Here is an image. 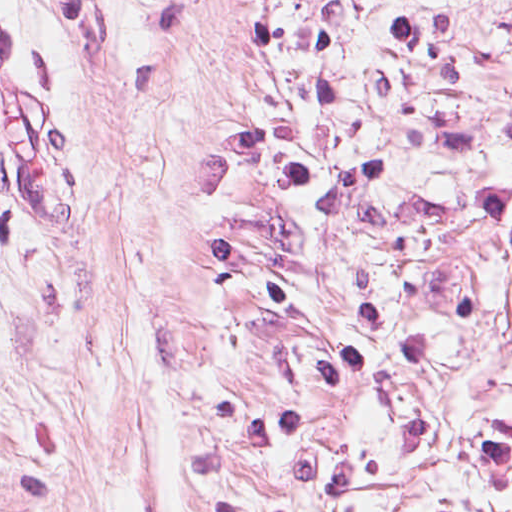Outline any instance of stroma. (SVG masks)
<instances>
[{
    "label": "stroma",
    "instance_id": "35a3bbf8",
    "mask_svg": "<svg viewBox=\"0 0 512 512\" xmlns=\"http://www.w3.org/2000/svg\"><path fill=\"white\" fill-rule=\"evenodd\" d=\"M20 0H0V90Z\"/></svg>",
    "mask_w": 512,
    "mask_h": 512
}]
</instances>
